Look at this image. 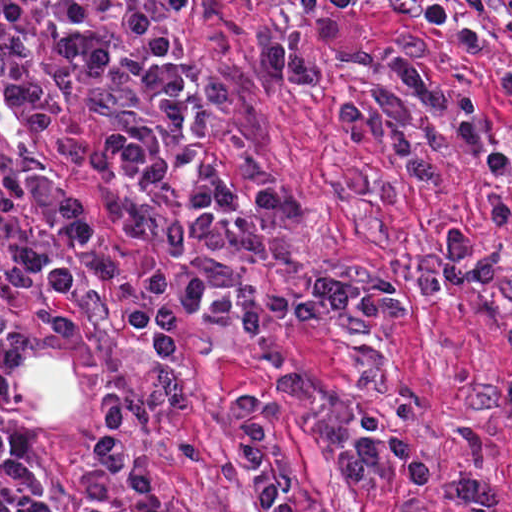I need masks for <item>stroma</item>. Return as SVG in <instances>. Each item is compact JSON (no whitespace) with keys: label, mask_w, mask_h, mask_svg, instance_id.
<instances>
[{"label":"stroma","mask_w":512,"mask_h":512,"mask_svg":"<svg viewBox=\"0 0 512 512\" xmlns=\"http://www.w3.org/2000/svg\"><path fill=\"white\" fill-rule=\"evenodd\" d=\"M1 1H114L164 30L187 54L191 105L181 174L188 187L209 168H226L242 190L281 203L278 237H251L215 275L210 296L264 286L295 296L332 275L408 285L417 259L435 258L449 230L472 232L473 256L486 252L490 175L468 156L454 124L439 184L420 187L402 172L389 143L351 145L336 120L345 106L381 88L397 93L420 119L426 105L385 69H363L318 53L320 88L259 82L271 40L302 45L313 21L353 25L373 49L394 53L420 40L421 66L445 83L469 86L481 104V136L499 152L512 134V102L496 94L512 76V40L491 18L475 27L487 49L466 54L424 23L386 13L391 0H0V234L49 251L67 245L41 228L28 173L97 191L107 164L80 159L54 143L1 93ZM463 12L462 0H445ZM506 4L512 0H493ZM512 215V174L503 184ZM119 265L112 279L88 264L75 291L79 330L56 334L35 295L0 283V429L31 444V464L55 512H91L76 478L82 443L98 427L111 392L127 402V451L147 462L163 499L189 512H271L247 483L239 461L237 402L265 405L280 453L297 470V512H461L453 496L466 471L456 443L471 410L512 385V228L495 237L497 282L486 290L446 286L416 303L413 318L370 320L358 313L318 321L271 322L285 365L305 383V399L286 401L265 383L242 328L176 320V352L159 356L122 324L119 310L159 274V260L105 216L100 227ZM27 346H49L87 379V412L66 428H29L1 390V368ZM483 443L475 476L512 512V413L476 423ZM404 429L436 468V487L411 493L395 470L354 485L341 463L361 436ZM0 512H16L0 496Z\"/></svg>","instance_id":"35a3bbf8"}]
</instances>
